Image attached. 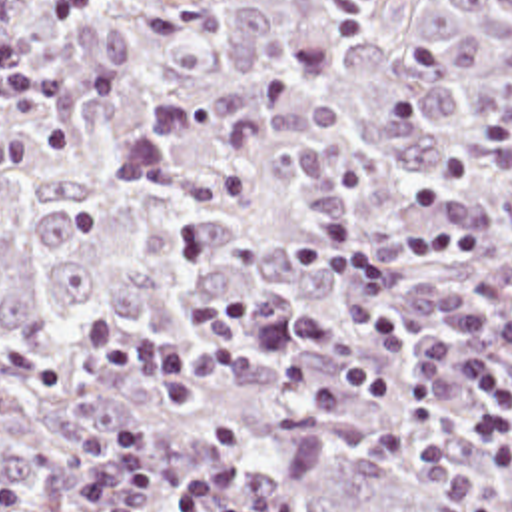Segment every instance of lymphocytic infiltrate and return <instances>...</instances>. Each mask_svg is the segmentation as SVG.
I'll list each match as a JSON object with an SVG mask.
<instances>
[{"instance_id":"lymphocytic-infiltrate-1","label":"lymphocytic infiltrate","mask_w":512,"mask_h":512,"mask_svg":"<svg viewBox=\"0 0 512 512\" xmlns=\"http://www.w3.org/2000/svg\"><path fill=\"white\" fill-rule=\"evenodd\" d=\"M103 0H45L49 27L87 11ZM400 249L414 259H476V229L424 227L402 237ZM294 259L310 261L324 275L350 273L356 279L354 309L360 325L388 349H408L400 317L382 305L396 289V277L380 251L350 215H334L310 233L286 239ZM254 297L248 289L217 293L185 305L175 341L151 337L143 317L127 307H103L87 321L77 353L85 374L129 376L165 396L175 410H197L203 386L227 360H258L298 351L302 359L282 364L278 376L294 398L314 410H344L354 396H402V382L362 362L328 357L338 325L328 315H308L246 329ZM464 368L484 384V400L464 432L470 442H496L512 424V384L476 349L464 351ZM77 494L99 512H145L155 506L173 512H280L276 494L252 498L238 486L229 466L181 480L161 478L147 458V434L135 418L117 424L87 470ZM0 512H37L29 490L19 484L0 488Z\"/></svg>"}]
</instances>
